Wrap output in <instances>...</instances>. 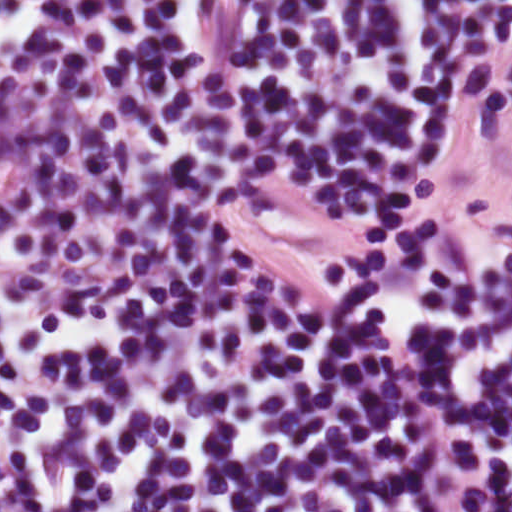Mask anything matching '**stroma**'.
Returning a JSON list of instances; mask_svg holds the SVG:
<instances>
[{
	"label": "stroma",
	"mask_w": 512,
	"mask_h": 512,
	"mask_svg": "<svg viewBox=\"0 0 512 512\" xmlns=\"http://www.w3.org/2000/svg\"><path fill=\"white\" fill-rule=\"evenodd\" d=\"M252 226L278 250L335 262H367L435 230L504 232L448 104L390 204L272 192L255 196Z\"/></svg>",
	"instance_id": "35a3bbf8"
}]
</instances>
